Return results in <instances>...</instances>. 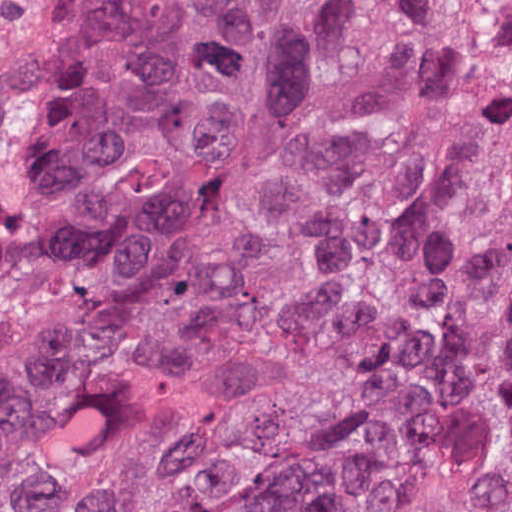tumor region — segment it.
I'll return each instance as SVG.
<instances>
[{
	"instance_id": "1",
	"label": "tumor region",
	"mask_w": 512,
	"mask_h": 512,
	"mask_svg": "<svg viewBox=\"0 0 512 512\" xmlns=\"http://www.w3.org/2000/svg\"><path fill=\"white\" fill-rule=\"evenodd\" d=\"M0 512H512V0H87L0 98Z\"/></svg>"
}]
</instances>
